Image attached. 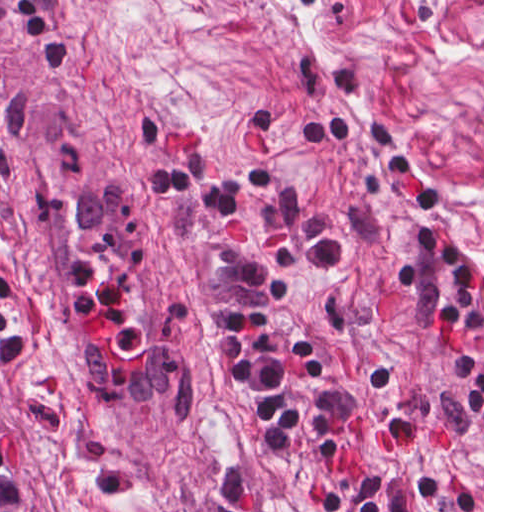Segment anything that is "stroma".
Listing matches in <instances>:
<instances>
[{"instance_id":"stroma-1","label":"stroma","mask_w":512,"mask_h":512,"mask_svg":"<svg viewBox=\"0 0 512 512\" xmlns=\"http://www.w3.org/2000/svg\"><path fill=\"white\" fill-rule=\"evenodd\" d=\"M317 0H0V352Z\"/></svg>"}]
</instances>
